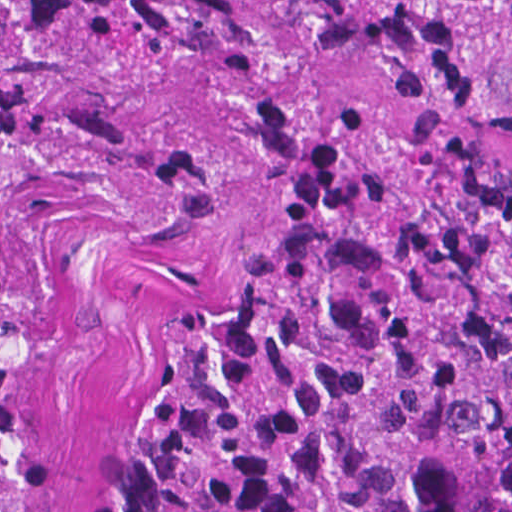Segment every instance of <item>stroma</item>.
<instances>
[{"instance_id":"35a3bbf8","label":"stroma","mask_w":512,"mask_h":512,"mask_svg":"<svg viewBox=\"0 0 512 512\" xmlns=\"http://www.w3.org/2000/svg\"><path fill=\"white\" fill-rule=\"evenodd\" d=\"M56 175L19 190L4 250L0 512H91L142 346L227 285L252 245L230 180Z\"/></svg>"}]
</instances>
